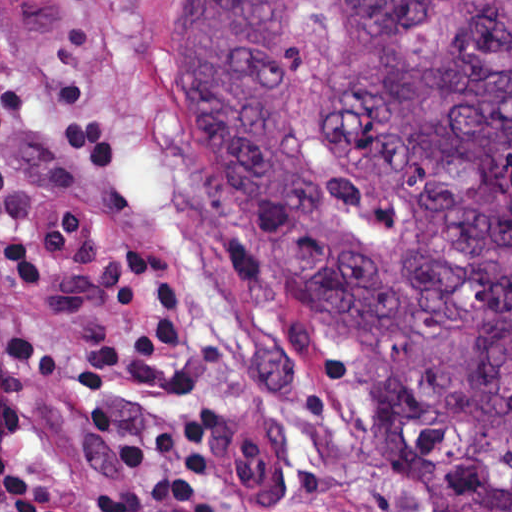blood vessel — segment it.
I'll return each mask as SVG.
<instances>
[{
	"label": "blood vessel",
	"mask_w": 512,
	"mask_h": 512,
	"mask_svg": "<svg viewBox=\"0 0 512 512\" xmlns=\"http://www.w3.org/2000/svg\"><path fill=\"white\" fill-rule=\"evenodd\" d=\"M211 451L228 495L255 501L280 469V429L255 406L236 405L213 423Z\"/></svg>",
	"instance_id": "1"
}]
</instances>
